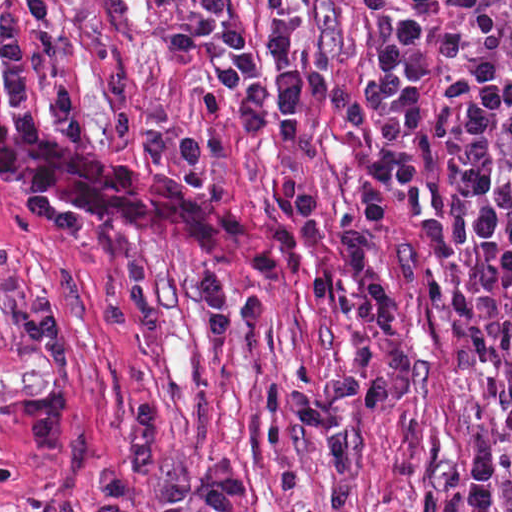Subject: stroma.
<instances>
[{
	"label": "stroma",
	"mask_w": 512,
	"mask_h": 512,
	"mask_svg": "<svg viewBox=\"0 0 512 512\" xmlns=\"http://www.w3.org/2000/svg\"><path fill=\"white\" fill-rule=\"evenodd\" d=\"M24 0H0V25ZM509 0H314L290 14L317 69L358 80L384 28L401 10L425 19L429 69L425 177L417 187L378 191L386 209L381 257L399 297L413 351L411 385L384 405L342 412L363 461L352 499L339 512H465L471 450L485 429L505 422L496 377L468 372L447 340L442 276L423 237L427 220L443 228L461 210L446 135V81L455 44L492 8ZM253 38L271 18L264 0H228ZM193 0H55L52 16L27 45V101L19 115L2 81L0 130L82 151L152 181L192 188L209 202L203 222H138L55 197L0 187V512H94L98 470L123 460V426L151 402L163 465L179 481L207 456L235 463L247 478L244 512H329L331 451L288 414L289 394L317 389L354 367V336L316 308L310 282L337 278L379 370V342L361 317L362 289L342 249L339 221L362 212L370 167L345 120L314 106L301 140L273 130L241 133L240 108L208 114L200 95L207 63L173 50L167 35ZM131 78L141 107L167 104L173 125L221 134L229 155L215 165L254 224L282 221L278 196L299 175L320 201L319 240L291 279H272L241 263L226 241L209 192L169 161L159 165L143 136L117 137L109 80ZM70 90L86 147H68L55 125V88ZM211 266L236 299L265 294L271 319L247 324L234 310L230 335L214 340L195 285ZM140 512H163L157 487L142 482ZM198 512H206L204 510ZM491 512H512V452L504 455Z\"/></svg>",
	"instance_id": "35a3bbf8"
}]
</instances>
